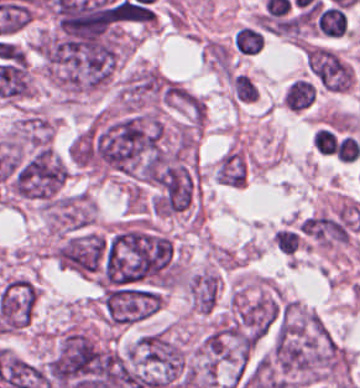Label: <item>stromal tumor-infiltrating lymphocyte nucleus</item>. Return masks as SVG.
Wrapping results in <instances>:
<instances>
[{"label":"stromal tumor-infiltrating lymphocyte nucleus","mask_w":360,"mask_h":388,"mask_svg":"<svg viewBox=\"0 0 360 388\" xmlns=\"http://www.w3.org/2000/svg\"><path fill=\"white\" fill-rule=\"evenodd\" d=\"M316 97L315 83L301 77L287 86L282 103L293 112H304L313 105Z\"/></svg>","instance_id":"obj_1"},{"label":"stromal tumor-infiltrating lymphocyte nucleus","mask_w":360,"mask_h":388,"mask_svg":"<svg viewBox=\"0 0 360 388\" xmlns=\"http://www.w3.org/2000/svg\"><path fill=\"white\" fill-rule=\"evenodd\" d=\"M235 49L239 55L245 56L262 52L261 31L256 25H242L235 31Z\"/></svg>","instance_id":"obj_2"},{"label":"stromal tumor-infiltrating lymphocyte nucleus","mask_w":360,"mask_h":388,"mask_svg":"<svg viewBox=\"0 0 360 388\" xmlns=\"http://www.w3.org/2000/svg\"><path fill=\"white\" fill-rule=\"evenodd\" d=\"M316 25L327 35L341 36L348 21L344 12L336 6L329 5L318 13Z\"/></svg>","instance_id":"obj_3"},{"label":"stromal tumor-infiltrating lymphocyte nucleus","mask_w":360,"mask_h":388,"mask_svg":"<svg viewBox=\"0 0 360 388\" xmlns=\"http://www.w3.org/2000/svg\"><path fill=\"white\" fill-rule=\"evenodd\" d=\"M235 95L237 99L254 101L258 97V90L253 80L243 73L234 76Z\"/></svg>","instance_id":"obj_4"}]
</instances>
